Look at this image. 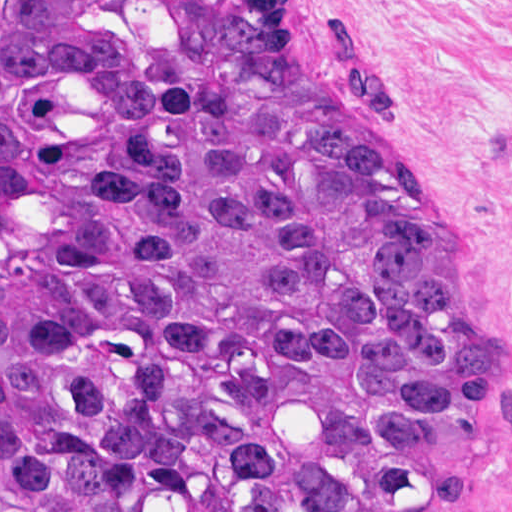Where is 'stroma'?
Segmentation results:
<instances>
[{"instance_id":"obj_1","label":"stroma","mask_w":512,"mask_h":512,"mask_svg":"<svg viewBox=\"0 0 512 512\" xmlns=\"http://www.w3.org/2000/svg\"><path fill=\"white\" fill-rule=\"evenodd\" d=\"M301 56L387 114L508 342L512 428V0H280ZM449 512H512V437Z\"/></svg>"}]
</instances>
